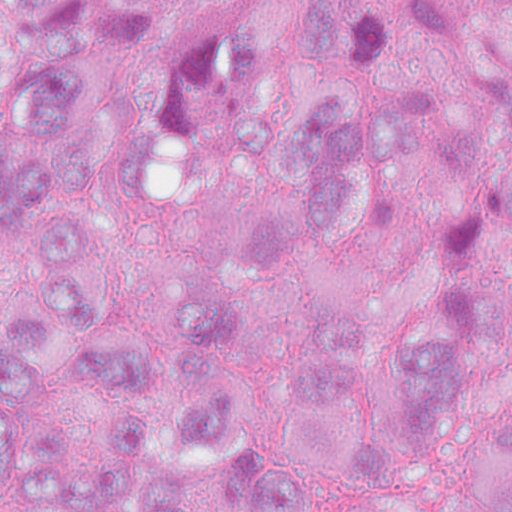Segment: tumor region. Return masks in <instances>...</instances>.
I'll return each mask as SVG.
<instances>
[{"label": "tumor region", "instance_id": "tumor-region-1", "mask_svg": "<svg viewBox=\"0 0 512 512\" xmlns=\"http://www.w3.org/2000/svg\"><path fill=\"white\" fill-rule=\"evenodd\" d=\"M177 0H0V498L51 512H309L299 474L364 490L395 448L359 374L385 360L408 435L434 440L469 390L451 339L474 330L479 279L414 314L338 298L298 395L248 409L229 357L261 279L334 250L411 163L434 159L512 241V166L452 143L412 107L307 88L238 123L223 224L178 282L173 339L123 348L109 325V205L154 174L103 106L99 54L149 44ZM218 39L328 64H390L437 44H512L499 0H180ZM512 512V404L459 453L439 503Z\"/></svg>", "mask_w": 512, "mask_h": 512}]
</instances>
